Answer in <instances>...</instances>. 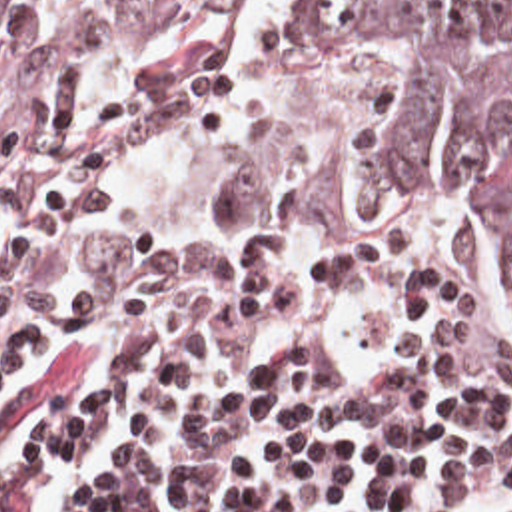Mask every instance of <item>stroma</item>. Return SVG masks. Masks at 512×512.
I'll return each mask as SVG.
<instances>
[{"label": "stroma", "instance_id": "stroma-1", "mask_svg": "<svg viewBox=\"0 0 512 512\" xmlns=\"http://www.w3.org/2000/svg\"><path fill=\"white\" fill-rule=\"evenodd\" d=\"M202 73H246L266 85V113L228 141L182 155L148 171L132 185V211L144 245L166 253H256L352 243L374 231L390 199L432 203L426 179H400L374 187L364 211H290L252 201L248 173L270 157L290 133L294 97L284 73L266 53H138L108 59L36 91L0 101V161L12 159L38 133L46 109L64 85L120 77L134 93L172 91ZM485 229V227H483ZM491 241V313L483 325H452L400 317L370 297L266 295L174 297L116 305L90 321L128 323L142 317L192 311L222 303H272L306 317H356L380 323H422L512 355V255L507 241ZM2 335L0 367L62 333Z\"/></svg>", "mask_w": 512, "mask_h": 512}]
</instances>
